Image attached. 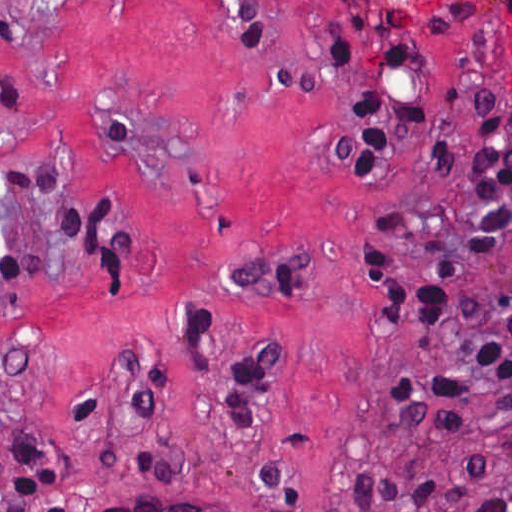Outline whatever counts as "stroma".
Listing matches in <instances>:
<instances>
[{"mask_svg": "<svg viewBox=\"0 0 512 512\" xmlns=\"http://www.w3.org/2000/svg\"><path fill=\"white\" fill-rule=\"evenodd\" d=\"M327 37L351 42L358 69L334 62ZM421 57L382 67L391 46ZM363 82L407 95H450L406 131L381 173L337 154L360 111L346 90ZM471 104L512 148V21L489 0H0V170L34 156L61 161L72 183L49 194L0 184V512L14 427L52 460L59 505L96 512L127 498L187 502L216 512H362L347 497L363 459L402 476L457 481L480 456L488 485L512 484V428L497 404L463 408L470 430L431 423L393 446L384 394L403 367L445 362L470 343L462 300L512 287V231L489 257L465 247L473 220L465 185L474 142ZM446 138L444 176L433 140ZM92 205L85 253L55 213ZM406 210L389 240L399 276L416 282L437 257L458 280L432 329L385 316L364 291L354 230L377 233ZM114 212L137 250L106 282L104 240ZM271 260L310 274L304 299L218 291L235 265ZM198 301L211 321L193 342ZM285 339L263 389L258 431H241L227 384L258 341ZM161 362L150 418L130 406L119 373L140 352ZM89 389L98 416L73 413ZM136 457L180 466V481L128 474ZM272 461L302 480L305 509L274 500L255 474Z\"/></svg>", "mask_w": 512, "mask_h": 512, "instance_id": "35a3bbf8", "label": "stroma"}]
</instances>
